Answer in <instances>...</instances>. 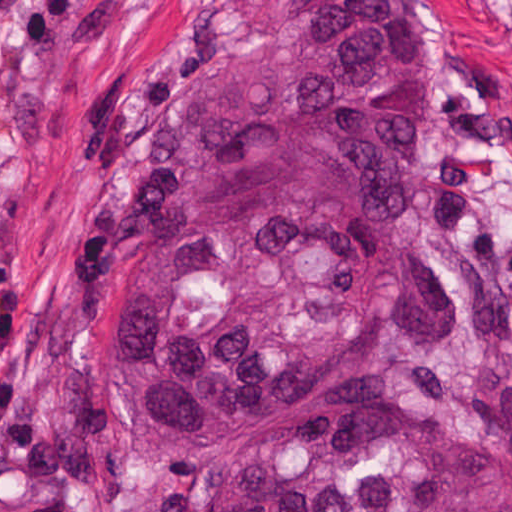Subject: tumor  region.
<instances>
[{
  "label": "tumor region",
  "mask_w": 512,
  "mask_h": 512,
  "mask_svg": "<svg viewBox=\"0 0 512 512\" xmlns=\"http://www.w3.org/2000/svg\"><path fill=\"white\" fill-rule=\"evenodd\" d=\"M441 43L410 0H319L162 105L105 199L87 297L168 512H512V440L395 387L458 327L414 162Z\"/></svg>",
  "instance_id": "e687c5a6"
}]
</instances>
